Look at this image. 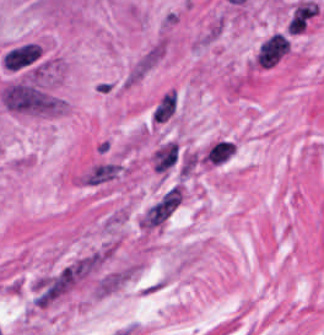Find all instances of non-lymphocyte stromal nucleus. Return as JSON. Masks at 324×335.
<instances>
[{"label": "non-lymphocyte stromal nucleus", "instance_id": "non-lymphocyte-stromal-nucleus-1", "mask_svg": "<svg viewBox=\"0 0 324 335\" xmlns=\"http://www.w3.org/2000/svg\"><path fill=\"white\" fill-rule=\"evenodd\" d=\"M5 108L20 113H51L58 100L32 80L17 78L1 88Z\"/></svg>", "mask_w": 324, "mask_h": 335}, {"label": "non-lymphocyte stromal nucleus", "instance_id": "non-lymphocyte-stromal-nucleus-2", "mask_svg": "<svg viewBox=\"0 0 324 335\" xmlns=\"http://www.w3.org/2000/svg\"><path fill=\"white\" fill-rule=\"evenodd\" d=\"M183 198V185L170 184L143 207L138 217L139 227L151 230L165 223L180 206Z\"/></svg>", "mask_w": 324, "mask_h": 335}, {"label": "non-lymphocyte stromal nucleus", "instance_id": "non-lymphocyte-stromal-nucleus-3", "mask_svg": "<svg viewBox=\"0 0 324 335\" xmlns=\"http://www.w3.org/2000/svg\"><path fill=\"white\" fill-rule=\"evenodd\" d=\"M39 56L40 49L37 43L31 40H23L8 48L1 60L3 65L17 71L33 66L38 61Z\"/></svg>", "mask_w": 324, "mask_h": 335}, {"label": "non-lymphocyte stromal nucleus", "instance_id": "non-lymphocyte-stromal-nucleus-4", "mask_svg": "<svg viewBox=\"0 0 324 335\" xmlns=\"http://www.w3.org/2000/svg\"><path fill=\"white\" fill-rule=\"evenodd\" d=\"M288 38L282 32H274L260 45L256 61L259 65L271 66L286 50Z\"/></svg>", "mask_w": 324, "mask_h": 335}, {"label": "non-lymphocyte stromal nucleus", "instance_id": "non-lymphocyte-stromal-nucleus-5", "mask_svg": "<svg viewBox=\"0 0 324 335\" xmlns=\"http://www.w3.org/2000/svg\"><path fill=\"white\" fill-rule=\"evenodd\" d=\"M179 160V149L176 142L165 140L153 151L150 163L155 171L167 172Z\"/></svg>", "mask_w": 324, "mask_h": 335}, {"label": "non-lymphocyte stromal nucleus", "instance_id": "non-lymphocyte-stromal-nucleus-6", "mask_svg": "<svg viewBox=\"0 0 324 335\" xmlns=\"http://www.w3.org/2000/svg\"><path fill=\"white\" fill-rule=\"evenodd\" d=\"M317 8L318 5L311 1L300 0L297 2L287 21L286 29L291 33H298L314 15Z\"/></svg>", "mask_w": 324, "mask_h": 335}, {"label": "non-lymphocyte stromal nucleus", "instance_id": "non-lymphocyte-stromal-nucleus-7", "mask_svg": "<svg viewBox=\"0 0 324 335\" xmlns=\"http://www.w3.org/2000/svg\"><path fill=\"white\" fill-rule=\"evenodd\" d=\"M234 151V142L231 139L219 138L211 143L202 155L203 162L220 164Z\"/></svg>", "mask_w": 324, "mask_h": 335}, {"label": "non-lymphocyte stromal nucleus", "instance_id": "non-lymphocyte-stromal-nucleus-8", "mask_svg": "<svg viewBox=\"0 0 324 335\" xmlns=\"http://www.w3.org/2000/svg\"><path fill=\"white\" fill-rule=\"evenodd\" d=\"M119 170V163L102 162L87 172L82 180L89 184H99L115 176Z\"/></svg>", "mask_w": 324, "mask_h": 335}, {"label": "non-lymphocyte stromal nucleus", "instance_id": "non-lymphocyte-stromal-nucleus-9", "mask_svg": "<svg viewBox=\"0 0 324 335\" xmlns=\"http://www.w3.org/2000/svg\"><path fill=\"white\" fill-rule=\"evenodd\" d=\"M176 106V89L173 87L164 92L157 100L152 112V119H166Z\"/></svg>", "mask_w": 324, "mask_h": 335}]
</instances>
